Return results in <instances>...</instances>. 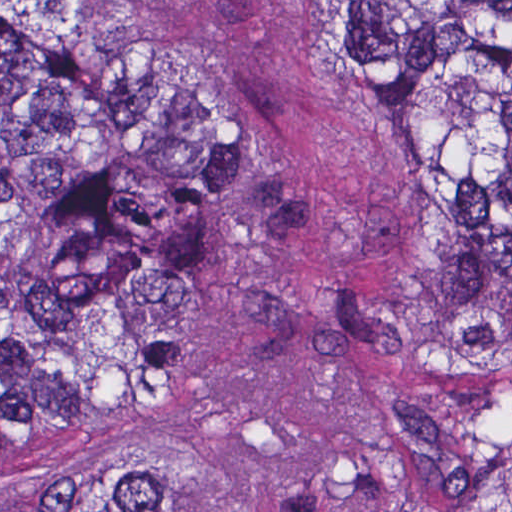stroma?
I'll list each match as a JSON object with an SVG mask.
<instances>
[{"instance_id": "35a3bbf8", "label": "stroma", "mask_w": 512, "mask_h": 512, "mask_svg": "<svg viewBox=\"0 0 512 512\" xmlns=\"http://www.w3.org/2000/svg\"><path fill=\"white\" fill-rule=\"evenodd\" d=\"M0 1L166 49L292 163L295 214L213 268L161 343L150 418L174 512H426L385 404L427 293L422 175L389 96L352 79L343 1L512 0Z\"/></svg>"}]
</instances>
